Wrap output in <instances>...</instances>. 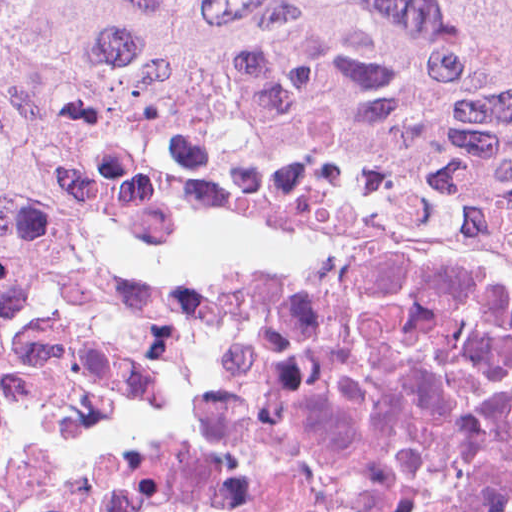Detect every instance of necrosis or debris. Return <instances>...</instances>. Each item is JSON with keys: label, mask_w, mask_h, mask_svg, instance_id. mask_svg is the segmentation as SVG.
I'll use <instances>...</instances> for the list:
<instances>
[{"label": "necrosis or debris", "mask_w": 512, "mask_h": 512, "mask_svg": "<svg viewBox=\"0 0 512 512\" xmlns=\"http://www.w3.org/2000/svg\"><path fill=\"white\" fill-rule=\"evenodd\" d=\"M0 512H512V242L117 169L0 289Z\"/></svg>", "instance_id": "necrosis-or-debris-1"}]
</instances>
